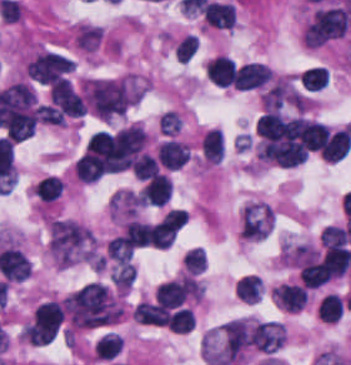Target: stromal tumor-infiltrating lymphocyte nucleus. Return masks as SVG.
<instances>
[{
	"label": "stromal tumor-infiltrating lymphocyte nucleus",
	"instance_id": "bc302bb0",
	"mask_svg": "<svg viewBox=\"0 0 351 365\" xmlns=\"http://www.w3.org/2000/svg\"><path fill=\"white\" fill-rule=\"evenodd\" d=\"M272 75L266 64L247 62L235 68L233 82L235 89L250 90L263 86Z\"/></svg>",
	"mask_w": 351,
	"mask_h": 365
},
{
	"label": "stromal tumor-infiltrating lymphocyte nucleus",
	"instance_id": "52c7bb5b",
	"mask_svg": "<svg viewBox=\"0 0 351 365\" xmlns=\"http://www.w3.org/2000/svg\"><path fill=\"white\" fill-rule=\"evenodd\" d=\"M156 156L165 168H179L189 156V145L168 139L160 143Z\"/></svg>",
	"mask_w": 351,
	"mask_h": 365
},
{
	"label": "stromal tumor-infiltrating lymphocyte nucleus",
	"instance_id": "3290ff9b",
	"mask_svg": "<svg viewBox=\"0 0 351 365\" xmlns=\"http://www.w3.org/2000/svg\"><path fill=\"white\" fill-rule=\"evenodd\" d=\"M350 146V133L344 127L328 134L320 154L324 160L338 161L347 154Z\"/></svg>",
	"mask_w": 351,
	"mask_h": 365
},
{
	"label": "stromal tumor-infiltrating lymphocyte nucleus",
	"instance_id": "abfb95fc",
	"mask_svg": "<svg viewBox=\"0 0 351 365\" xmlns=\"http://www.w3.org/2000/svg\"><path fill=\"white\" fill-rule=\"evenodd\" d=\"M201 11L204 19L217 27H231L235 22L234 5L225 1L209 0Z\"/></svg>",
	"mask_w": 351,
	"mask_h": 365
},
{
	"label": "stromal tumor-infiltrating lymphocyte nucleus",
	"instance_id": "9ea309e8",
	"mask_svg": "<svg viewBox=\"0 0 351 365\" xmlns=\"http://www.w3.org/2000/svg\"><path fill=\"white\" fill-rule=\"evenodd\" d=\"M200 149L211 163H220L224 155V135L221 130L210 129L200 140Z\"/></svg>",
	"mask_w": 351,
	"mask_h": 365
},
{
	"label": "stromal tumor-infiltrating lymphocyte nucleus",
	"instance_id": "f3e2335f",
	"mask_svg": "<svg viewBox=\"0 0 351 365\" xmlns=\"http://www.w3.org/2000/svg\"><path fill=\"white\" fill-rule=\"evenodd\" d=\"M62 179L55 174H47L40 178L32 188L41 202H49L56 199L62 192Z\"/></svg>",
	"mask_w": 351,
	"mask_h": 365
},
{
	"label": "stromal tumor-infiltrating lymphocyte nucleus",
	"instance_id": "4f13568d",
	"mask_svg": "<svg viewBox=\"0 0 351 365\" xmlns=\"http://www.w3.org/2000/svg\"><path fill=\"white\" fill-rule=\"evenodd\" d=\"M235 289L243 302L256 303L263 290V283L260 277L252 273L239 278Z\"/></svg>",
	"mask_w": 351,
	"mask_h": 365
},
{
	"label": "stromal tumor-infiltrating lymphocyte nucleus",
	"instance_id": "2a367800",
	"mask_svg": "<svg viewBox=\"0 0 351 365\" xmlns=\"http://www.w3.org/2000/svg\"><path fill=\"white\" fill-rule=\"evenodd\" d=\"M74 170L80 182H94L102 174L101 162L91 155H81L75 162Z\"/></svg>",
	"mask_w": 351,
	"mask_h": 365
},
{
	"label": "stromal tumor-infiltrating lymphocyte nucleus",
	"instance_id": "4803ca6d",
	"mask_svg": "<svg viewBox=\"0 0 351 365\" xmlns=\"http://www.w3.org/2000/svg\"><path fill=\"white\" fill-rule=\"evenodd\" d=\"M133 173L140 180H147L159 173L156 160L150 153H142L131 165Z\"/></svg>",
	"mask_w": 351,
	"mask_h": 365
},
{
	"label": "stromal tumor-infiltrating lymphocyte nucleus",
	"instance_id": "4245b91a",
	"mask_svg": "<svg viewBox=\"0 0 351 365\" xmlns=\"http://www.w3.org/2000/svg\"><path fill=\"white\" fill-rule=\"evenodd\" d=\"M188 273H197L206 266V256L200 247H193L181 258Z\"/></svg>",
	"mask_w": 351,
	"mask_h": 365
},
{
	"label": "stromal tumor-infiltrating lymphocyte nucleus",
	"instance_id": "4c9ddf68",
	"mask_svg": "<svg viewBox=\"0 0 351 365\" xmlns=\"http://www.w3.org/2000/svg\"><path fill=\"white\" fill-rule=\"evenodd\" d=\"M197 47V36L186 34L175 47V58L180 63H187L194 54Z\"/></svg>",
	"mask_w": 351,
	"mask_h": 365
}]
</instances>
